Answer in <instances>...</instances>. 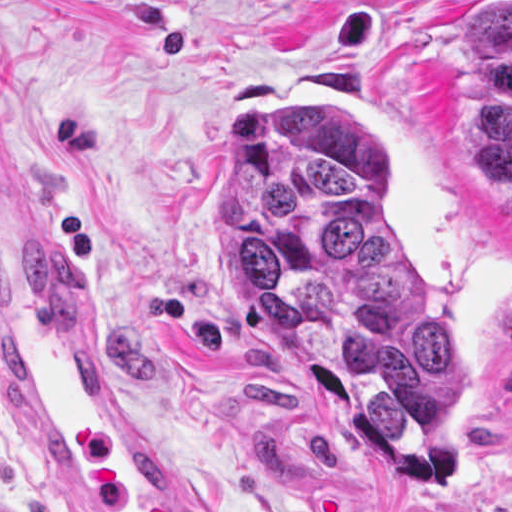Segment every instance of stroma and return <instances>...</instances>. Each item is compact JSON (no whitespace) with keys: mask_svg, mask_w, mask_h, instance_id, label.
Listing matches in <instances>:
<instances>
[{"mask_svg":"<svg viewBox=\"0 0 512 512\" xmlns=\"http://www.w3.org/2000/svg\"><path fill=\"white\" fill-rule=\"evenodd\" d=\"M512 0H0V189L222 512H512V201L459 146L471 28ZM245 112H355L378 200L461 348L434 472L251 332L214 145ZM0 512H68L0 360Z\"/></svg>","mask_w":512,"mask_h":512,"instance_id":"1","label":"stroma"}]
</instances>
